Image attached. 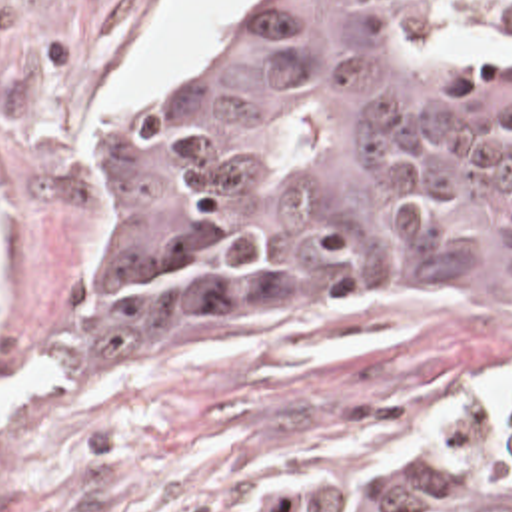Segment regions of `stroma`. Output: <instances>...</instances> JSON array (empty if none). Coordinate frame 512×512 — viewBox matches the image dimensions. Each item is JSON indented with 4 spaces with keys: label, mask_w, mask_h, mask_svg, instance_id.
<instances>
[{
    "label": "stroma",
    "mask_w": 512,
    "mask_h": 512,
    "mask_svg": "<svg viewBox=\"0 0 512 512\" xmlns=\"http://www.w3.org/2000/svg\"><path fill=\"white\" fill-rule=\"evenodd\" d=\"M169 0H0V384L35 364L63 388L0 426V512H243L297 472L361 458L512 386V302L427 284L301 304L283 284L191 302L141 376L65 350L95 306L119 192L95 144L239 52L269 0L139 112H107ZM445 34L437 54H507Z\"/></svg>",
    "instance_id": "1"
}]
</instances>
